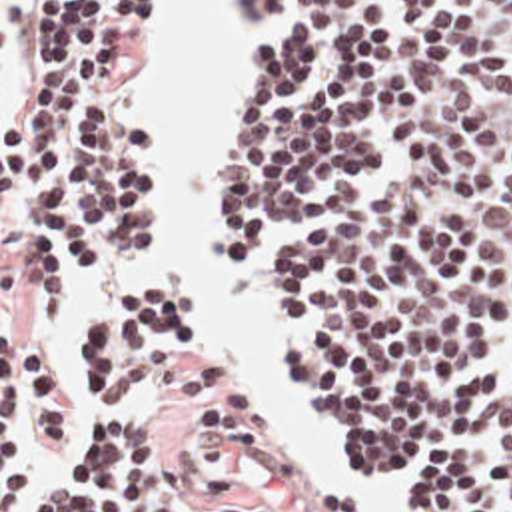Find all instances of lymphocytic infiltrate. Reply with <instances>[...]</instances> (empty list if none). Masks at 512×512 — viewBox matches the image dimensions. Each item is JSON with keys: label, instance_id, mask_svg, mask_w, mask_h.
I'll use <instances>...</instances> for the list:
<instances>
[{"label": "lymphocytic infiltrate", "instance_id": "1", "mask_svg": "<svg viewBox=\"0 0 512 512\" xmlns=\"http://www.w3.org/2000/svg\"><path fill=\"white\" fill-rule=\"evenodd\" d=\"M288 4L240 99L226 239L256 265L317 231L272 255L266 287L305 409L369 493L512 512V0H228V31H268ZM158 26L160 0H24L2 173L34 321L160 245L150 145L114 113ZM192 331V299L162 277L92 293L72 333L78 429L58 361L2 341V512H282L232 473L196 481L174 451L192 429L238 455L274 441L212 355L178 371L156 421H134Z\"/></svg>", "mask_w": 512, "mask_h": 512}]
</instances>
